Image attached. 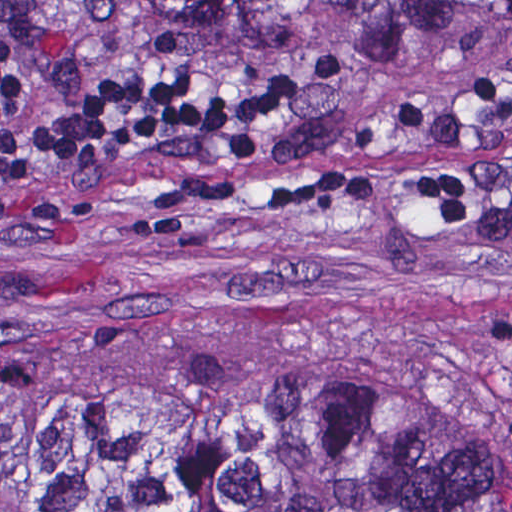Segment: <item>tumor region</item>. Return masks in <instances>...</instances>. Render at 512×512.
Here are the masks:
<instances>
[{
  "mask_svg": "<svg viewBox=\"0 0 512 512\" xmlns=\"http://www.w3.org/2000/svg\"><path fill=\"white\" fill-rule=\"evenodd\" d=\"M164 34H388L432 0H127ZM0 512H512V394L304 360L91 378L0 363Z\"/></svg>",
  "mask_w": 512,
  "mask_h": 512,
  "instance_id": "e687c5a6",
  "label": "tumor region"
}]
</instances>
